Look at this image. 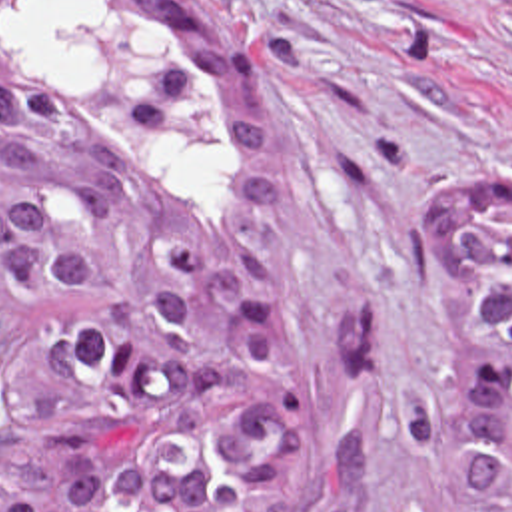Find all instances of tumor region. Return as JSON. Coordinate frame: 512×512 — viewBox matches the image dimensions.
Returning a JSON list of instances; mask_svg holds the SVG:
<instances>
[{"instance_id": "e687c5a6", "label": "tumor region", "mask_w": 512, "mask_h": 512, "mask_svg": "<svg viewBox=\"0 0 512 512\" xmlns=\"http://www.w3.org/2000/svg\"><path fill=\"white\" fill-rule=\"evenodd\" d=\"M257 55L205 0H0V512H369L285 307ZM440 369L385 416L452 512H512V179L424 217Z\"/></svg>"}]
</instances>
